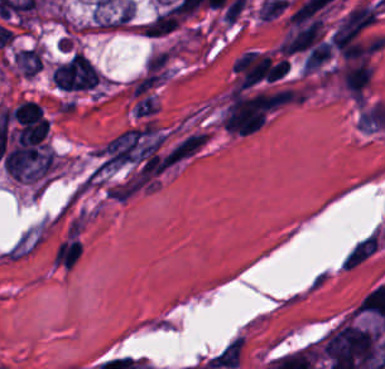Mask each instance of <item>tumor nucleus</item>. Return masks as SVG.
Segmentation results:
<instances>
[{
	"mask_svg": "<svg viewBox=\"0 0 385 369\" xmlns=\"http://www.w3.org/2000/svg\"><path fill=\"white\" fill-rule=\"evenodd\" d=\"M13 59L23 77H33L41 66V49L32 46L15 50Z\"/></svg>",
	"mask_w": 385,
	"mask_h": 369,
	"instance_id": "obj_1",
	"label": "tumor nucleus"
}]
</instances>
